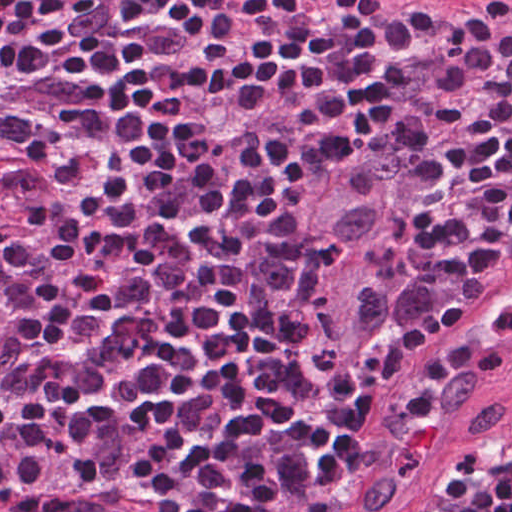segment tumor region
<instances>
[{
	"label": "tumor region",
	"instance_id": "obj_1",
	"mask_svg": "<svg viewBox=\"0 0 512 512\" xmlns=\"http://www.w3.org/2000/svg\"><path fill=\"white\" fill-rule=\"evenodd\" d=\"M357 163L332 172L321 190L298 274L304 327L338 365L355 361L377 336L392 228L388 168L375 162L347 173ZM483 490H494L492 479Z\"/></svg>",
	"mask_w": 512,
	"mask_h": 512
}]
</instances>
